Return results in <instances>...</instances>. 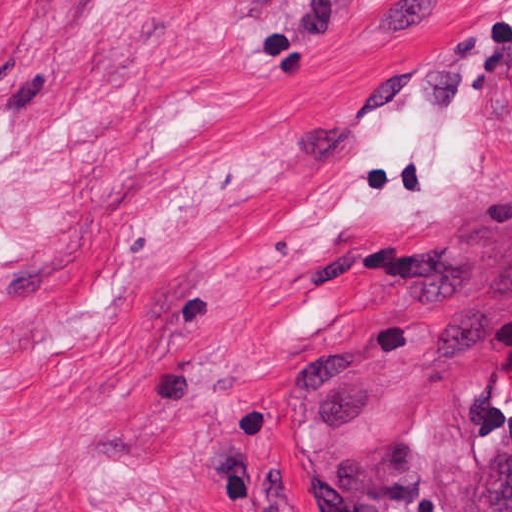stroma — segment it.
Masks as SVG:
<instances>
[{"label": "stroma", "instance_id": "obj_1", "mask_svg": "<svg viewBox=\"0 0 512 512\" xmlns=\"http://www.w3.org/2000/svg\"><path fill=\"white\" fill-rule=\"evenodd\" d=\"M512 447V0H0V512H453Z\"/></svg>", "mask_w": 512, "mask_h": 512}]
</instances>
